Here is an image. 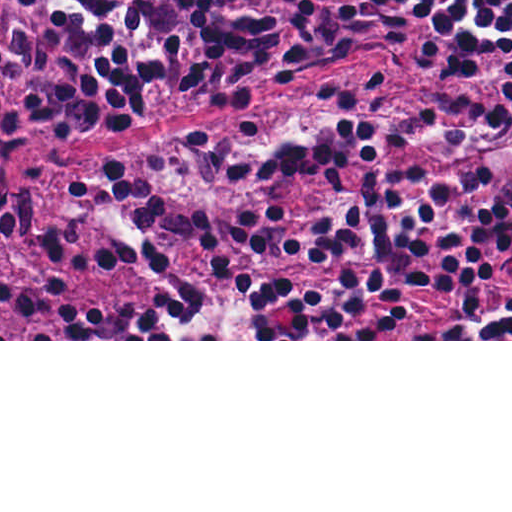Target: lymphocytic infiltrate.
I'll list each match as a JSON object with an SVG mask.
<instances>
[{"label": "lymphocytic infiltrate", "mask_w": 512, "mask_h": 512, "mask_svg": "<svg viewBox=\"0 0 512 512\" xmlns=\"http://www.w3.org/2000/svg\"><path fill=\"white\" fill-rule=\"evenodd\" d=\"M420 0H0V239L26 235L31 206L7 181L11 148L43 135L66 139L105 111L191 93L291 86L359 52L414 31ZM512 19V0H435L427 21L430 65L456 69ZM512 56V34L465 71ZM381 73L330 95L368 103ZM267 105L238 120L72 177L103 232L107 263L167 266L188 244L214 258V277L158 294L148 310L98 309L91 339H385L412 322L413 304L452 292L471 311L494 276L512 266V60L502 89L469 114L381 123L336 115L314 129L241 150L237 185L283 175L343 184L381 148L463 154L472 166L367 177L354 204L328 211L268 207L238 216L235 252L213 235V200H171L159 171L207 138L252 135ZM47 274L3 277L0 295L34 322L53 302L71 339L78 243L73 222L44 232ZM262 255L350 264L353 274L316 290H285L229 274ZM422 339H512V301L484 326L431 328Z\"/></svg>", "instance_id": "obj_1"}]
</instances>
